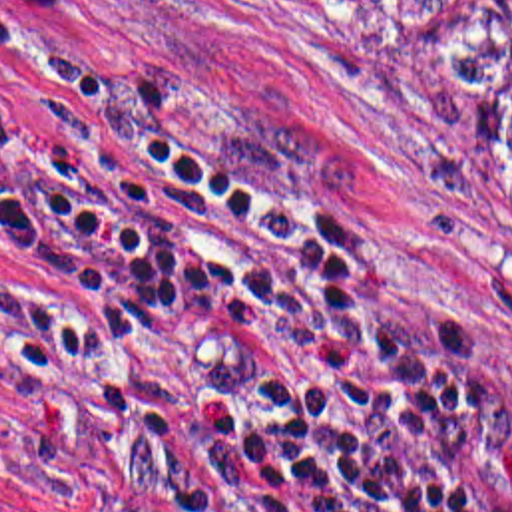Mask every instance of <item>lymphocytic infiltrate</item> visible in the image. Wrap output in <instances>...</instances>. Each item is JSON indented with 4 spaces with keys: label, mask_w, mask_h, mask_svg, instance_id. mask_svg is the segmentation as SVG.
<instances>
[{
    "label": "lymphocytic infiltrate",
    "mask_w": 512,
    "mask_h": 512,
    "mask_svg": "<svg viewBox=\"0 0 512 512\" xmlns=\"http://www.w3.org/2000/svg\"><path fill=\"white\" fill-rule=\"evenodd\" d=\"M0 250L40 318L2 431L72 512H512V393L333 214L28 21Z\"/></svg>",
    "instance_id": "f902f5d3"
}]
</instances>
